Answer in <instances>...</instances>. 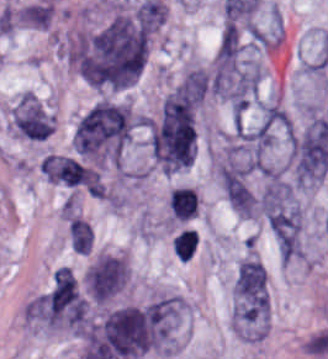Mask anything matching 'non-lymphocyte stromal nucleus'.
<instances>
[{
    "label": "non-lymphocyte stromal nucleus",
    "instance_id": "obj_4",
    "mask_svg": "<svg viewBox=\"0 0 328 359\" xmlns=\"http://www.w3.org/2000/svg\"><path fill=\"white\" fill-rule=\"evenodd\" d=\"M197 244L196 236L190 228H183L172 242L171 249L180 261H187Z\"/></svg>",
    "mask_w": 328,
    "mask_h": 359
},
{
    "label": "non-lymphocyte stromal nucleus",
    "instance_id": "obj_3",
    "mask_svg": "<svg viewBox=\"0 0 328 359\" xmlns=\"http://www.w3.org/2000/svg\"><path fill=\"white\" fill-rule=\"evenodd\" d=\"M168 205L171 217L187 220L197 212L195 190L190 186H176L169 190Z\"/></svg>",
    "mask_w": 328,
    "mask_h": 359
},
{
    "label": "non-lymphocyte stromal nucleus",
    "instance_id": "obj_2",
    "mask_svg": "<svg viewBox=\"0 0 328 359\" xmlns=\"http://www.w3.org/2000/svg\"><path fill=\"white\" fill-rule=\"evenodd\" d=\"M11 116L26 137H45L52 131V115L29 94H22Z\"/></svg>",
    "mask_w": 328,
    "mask_h": 359
},
{
    "label": "non-lymphocyte stromal nucleus",
    "instance_id": "obj_1",
    "mask_svg": "<svg viewBox=\"0 0 328 359\" xmlns=\"http://www.w3.org/2000/svg\"><path fill=\"white\" fill-rule=\"evenodd\" d=\"M232 317L239 338L260 339L268 323L266 272L259 259L242 257L232 279Z\"/></svg>",
    "mask_w": 328,
    "mask_h": 359
}]
</instances>
